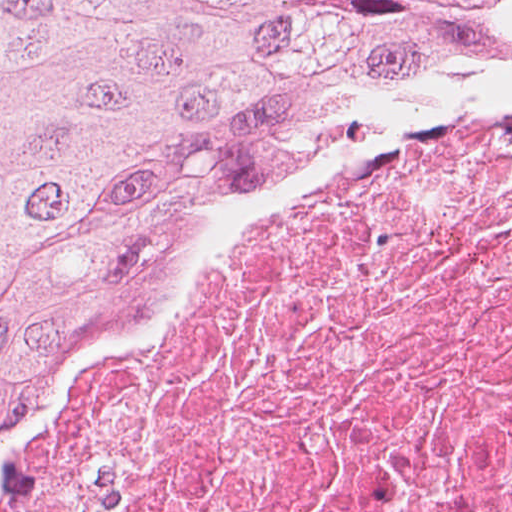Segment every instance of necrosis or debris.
Instances as JSON below:
<instances>
[{"instance_id":"necrosis-or-debris-1","label":"necrosis or debris","mask_w":512,"mask_h":512,"mask_svg":"<svg viewBox=\"0 0 512 512\" xmlns=\"http://www.w3.org/2000/svg\"><path fill=\"white\" fill-rule=\"evenodd\" d=\"M0 512H512V90L163 268L21 416Z\"/></svg>"}]
</instances>
